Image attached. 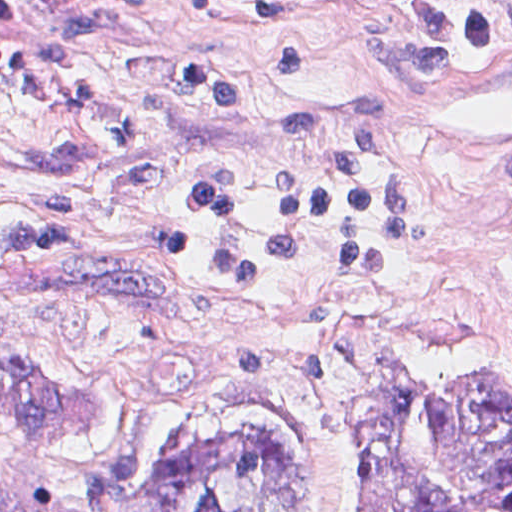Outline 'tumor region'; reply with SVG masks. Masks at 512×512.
<instances>
[{"label":"tumor region","instance_id":"obj_1","mask_svg":"<svg viewBox=\"0 0 512 512\" xmlns=\"http://www.w3.org/2000/svg\"><path fill=\"white\" fill-rule=\"evenodd\" d=\"M89 389L46 369L1 316V512H512V358L451 371L384 355L355 396L353 492L272 406H219L169 444L76 436Z\"/></svg>","mask_w":512,"mask_h":512}]
</instances>
